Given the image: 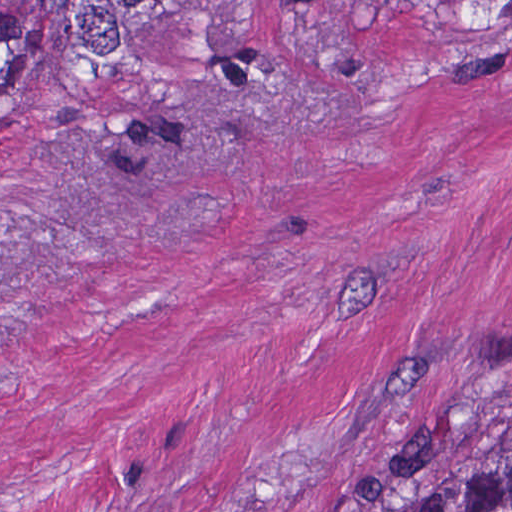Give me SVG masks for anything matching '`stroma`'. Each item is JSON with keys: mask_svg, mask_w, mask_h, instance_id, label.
<instances>
[{"mask_svg": "<svg viewBox=\"0 0 512 512\" xmlns=\"http://www.w3.org/2000/svg\"><path fill=\"white\" fill-rule=\"evenodd\" d=\"M512 437V23L174 0L0 101V512H385Z\"/></svg>", "mask_w": 512, "mask_h": 512, "instance_id": "35a3bbf8", "label": "stroma"}]
</instances>
